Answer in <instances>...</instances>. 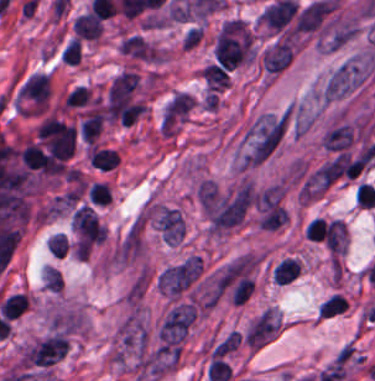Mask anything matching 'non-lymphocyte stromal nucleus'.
<instances>
[{"mask_svg":"<svg viewBox=\"0 0 375 381\" xmlns=\"http://www.w3.org/2000/svg\"><path fill=\"white\" fill-rule=\"evenodd\" d=\"M285 110H266L247 124L237 148V167L247 169L273 153L282 141Z\"/></svg>","mask_w":375,"mask_h":381,"instance_id":"non-lymphocyte-stromal-nucleus-1","label":"non-lymphocyte stromal nucleus"},{"mask_svg":"<svg viewBox=\"0 0 375 381\" xmlns=\"http://www.w3.org/2000/svg\"><path fill=\"white\" fill-rule=\"evenodd\" d=\"M374 71L373 53H354L329 73L320 94L333 103L347 98L361 89Z\"/></svg>","mask_w":375,"mask_h":381,"instance_id":"non-lymphocyte-stromal-nucleus-2","label":"non-lymphocyte stromal nucleus"},{"mask_svg":"<svg viewBox=\"0 0 375 381\" xmlns=\"http://www.w3.org/2000/svg\"><path fill=\"white\" fill-rule=\"evenodd\" d=\"M192 278V260L171 266L158 275L159 291L179 294Z\"/></svg>","mask_w":375,"mask_h":381,"instance_id":"non-lymphocyte-stromal-nucleus-3","label":"non-lymphocyte stromal nucleus"}]
</instances>
